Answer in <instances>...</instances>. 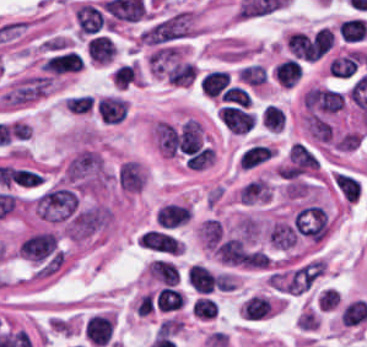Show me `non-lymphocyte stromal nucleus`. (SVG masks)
I'll list each match as a JSON object with an SVG mask.
<instances>
[{
  "label": "non-lymphocyte stromal nucleus",
  "instance_id": "3",
  "mask_svg": "<svg viewBox=\"0 0 367 347\" xmlns=\"http://www.w3.org/2000/svg\"><path fill=\"white\" fill-rule=\"evenodd\" d=\"M86 47L94 63L107 64L116 53L111 36L105 34L91 36Z\"/></svg>",
  "mask_w": 367,
  "mask_h": 347
},
{
  "label": "non-lymphocyte stromal nucleus",
  "instance_id": "1",
  "mask_svg": "<svg viewBox=\"0 0 367 347\" xmlns=\"http://www.w3.org/2000/svg\"><path fill=\"white\" fill-rule=\"evenodd\" d=\"M196 22L188 10H175L159 17L138 34L139 43L148 51L182 46L195 32Z\"/></svg>",
  "mask_w": 367,
  "mask_h": 347
},
{
  "label": "non-lymphocyte stromal nucleus",
  "instance_id": "2",
  "mask_svg": "<svg viewBox=\"0 0 367 347\" xmlns=\"http://www.w3.org/2000/svg\"><path fill=\"white\" fill-rule=\"evenodd\" d=\"M74 24L85 40L112 32L103 1L79 4L74 9Z\"/></svg>",
  "mask_w": 367,
  "mask_h": 347
}]
</instances>
